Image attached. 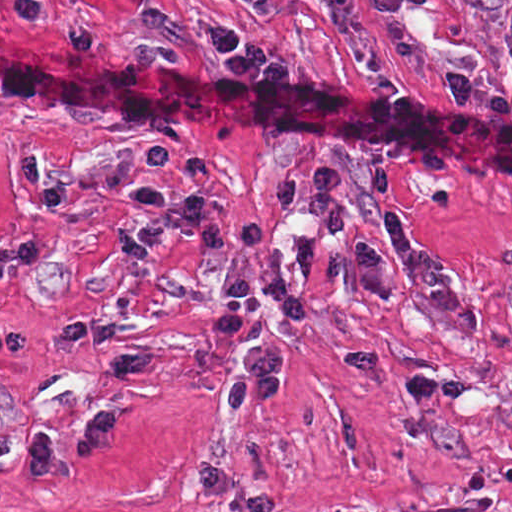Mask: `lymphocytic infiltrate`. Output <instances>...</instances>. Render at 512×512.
<instances>
[{
	"instance_id": "1",
	"label": "lymphocytic infiltrate",
	"mask_w": 512,
	"mask_h": 512,
	"mask_svg": "<svg viewBox=\"0 0 512 512\" xmlns=\"http://www.w3.org/2000/svg\"><path fill=\"white\" fill-rule=\"evenodd\" d=\"M255 12L270 9V0H239ZM216 64L228 74H283V63L241 26L210 21L202 29ZM512 54V27L509 34ZM342 176L335 167L311 171L302 183L295 170L282 169L269 179L273 208L285 218H304L325 237H338L348 228V214L340 209Z\"/></svg>"
}]
</instances>
